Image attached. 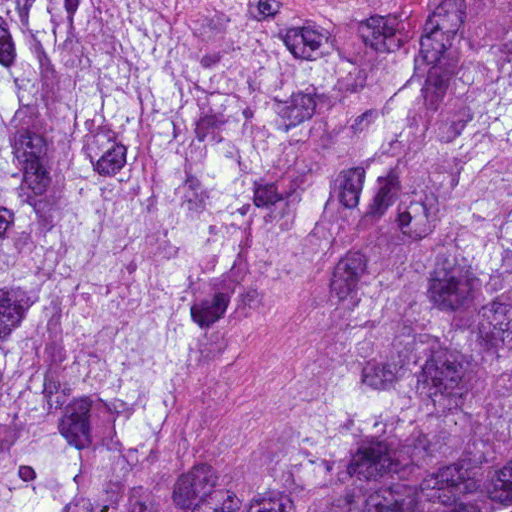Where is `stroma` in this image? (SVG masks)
I'll list each match as a JSON object with an SVG mask.
<instances>
[{
	"label": "stroma",
	"mask_w": 512,
	"mask_h": 512,
	"mask_svg": "<svg viewBox=\"0 0 512 512\" xmlns=\"http://www.w3.org/2000/svg\"><path fill=\"white\" fill-rule=\"evenodd\" d=\"M250 33H313L381 0H178ZM335 238L313 244L270 288L242 331L195 380L162 430L156 459L246 461L322 350V296Z\"/></svg>",
	"instance_id": "stroma-1"
}]
</instances>
